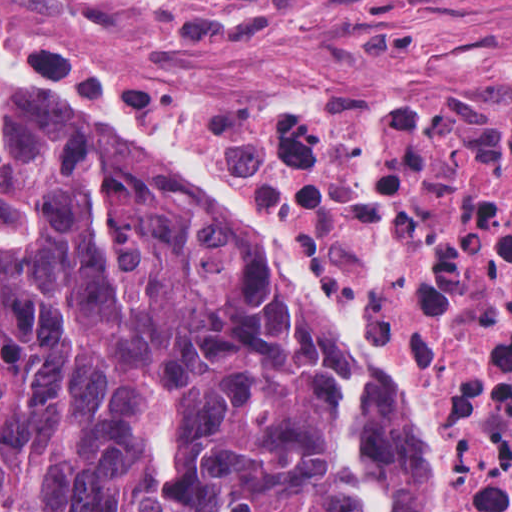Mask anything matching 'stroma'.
<instances>
[{"label":"stroma","mask_w":512,"mask_h":512,"mask_svg":"<svg viewBox=\"0 0 512 512\" xmlns=\"http://www.w3.org/2000/svg\"><path fill=\"white\" fill-rule=\"evenodd\" d=\"M51 38L146 88L493 96L512 90V0H7ZM47 19H45L39 12ZM19 117L150 175L291 313L329 373L349 356L371 398L421 450L429 512H456L447 391L374 353L198 175L106 105L70 109L0 69Z\"/></svg>","instance_id":"stroma-1"}]
</instances>
